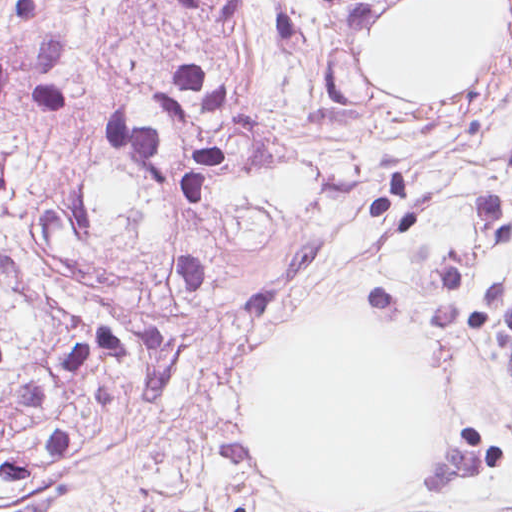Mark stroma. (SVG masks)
Wrapping results in <instances>:
<instances>
[{
	"label": "stroma",
	"instance_id": "35a3bbf8",
	"mask_svg": "<svg viewBox=\"0 0 512 512\" xmlns=\"http://www.w3.org/2000/svg\"><path fill=\"white\" fill-rule=\"evenodd\" d=\"M512 29V0H396L368 31L358 74L384 100H449L484 84ZM494 142L512 151V55L491 92ZM318 320L407 330L449 394L443 449L388 509L336 507L275 479L245 446L247 392L277 342ZM511 396L458 379L410 325L368 313L290 315L253 363L202 371L140 330L111 328L52 357L0 403V512H474Z\"/></svg>",
	"mask_w": 512,
	"mask_h": 512
}]
</instances>
